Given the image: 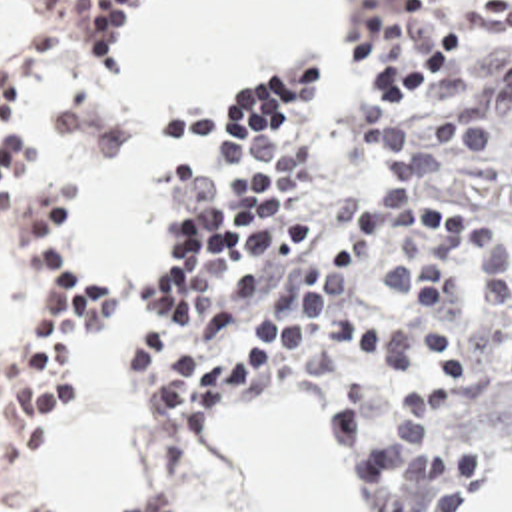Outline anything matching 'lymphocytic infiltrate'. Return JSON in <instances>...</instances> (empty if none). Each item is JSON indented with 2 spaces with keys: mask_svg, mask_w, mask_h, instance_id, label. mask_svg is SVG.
<instances>
[{
  "mask_svg": "<svg viewBox=\"0 0 512 512\" xmlns=\"http://www.w3.org/2000/svg\"><path fill=\"white\" fill-rule=\"evenodd\" d=\"M144 0H0V20L110 72ZM434 0H388L422 16ZM464 38H512V4L434 22L328 124L320 64L282 56L156 108L162 138L208 148L178 172L176 256L152 302L164 326L132 354L134 398L164 468L230 478L204 420L270 396L322 400L368 512H454L512 446V268L470 212L450 158L512 144V48L434 114L410 90ZM0 238L26 276V342L0 354V512H52L36 442L74 398V352L116 318L76 240L66 172H40L28 78L0 68ZM130 512H198L158 492Z\"/></svg>",
  "mask_w": 512,
  "mask_h": 512,
  "instance_id": "1",
  "label": "lymphocytic infiltrate"
}]
</instances>
